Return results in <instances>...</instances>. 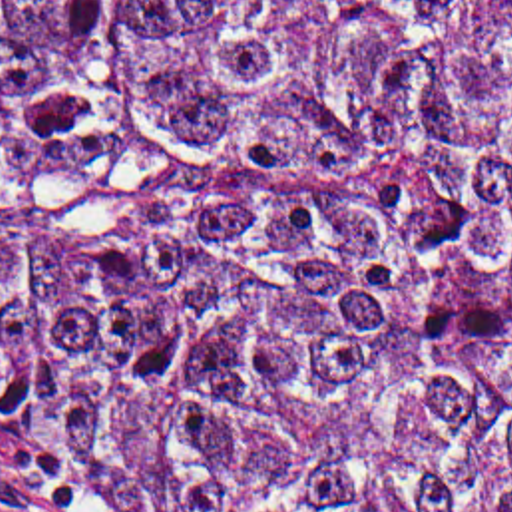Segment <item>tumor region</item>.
Returning a JSON list of instances; mask_svg holds the SVG:
<instances>
[{"label": "tumor region", "instance_id": "obj_1", "mask_svg": "<svg viewBox=\"0 0 512 512\" xmlns=\"http://www.w3.org/2000/svg\"><path fill=\"white\" fill-rule=\"evenodd\" d=\"M133 512H512V0H0V466Z\"/></svg>", "mask_w": 512, "mask_h": 512}]
</instances>
